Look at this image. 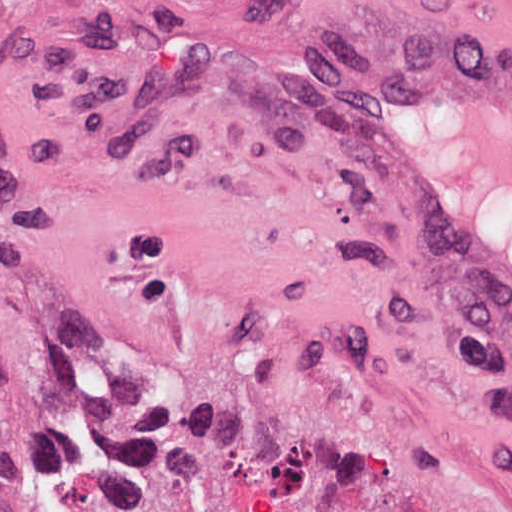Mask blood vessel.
I'll return each mask as SVG.
<instances>
[{"label": "blood vessel", "mask_w": 512, "mask_h": 512, "mask_svg": "<svg viewBox=\"0 0 512 512\" xmlns=\"http://www.w3.org/2000/svg\"><path fill=\"white\" fill-rule=\"evenodd\" d=\"M300 52L306 83L512 380V55Z\"/></svg>", "instance_id": "obj_1"}]
</instances>
